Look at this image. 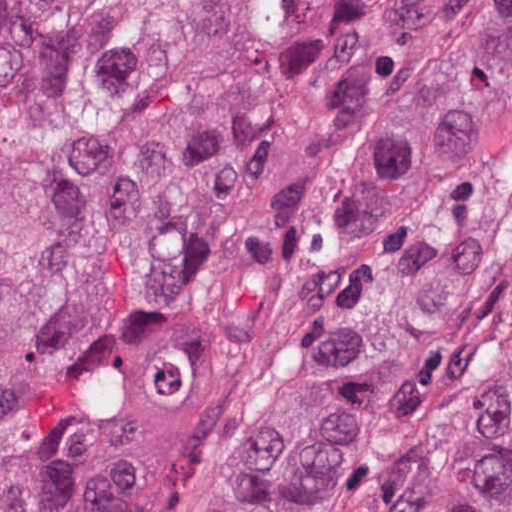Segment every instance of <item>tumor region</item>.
<instances>
[{
    "instance_id": "1",
    "label": "tumor region",
    "mask_w": 512,
    "mask_h": 512,
    "mask_svg": "<svg viewBox=\"0 0 512 512\" xmlns=\"http://www.w3.org/2000/svg\"><path fill=\"white\" fill-rule=\"evenodd\" d=\"M512 98V0H0V512H140L128 366L246 357ZM207 512H368L459 360L467 216L372 288ZM388 512H512V358Z\"/></svg>"
}]
</instances>
